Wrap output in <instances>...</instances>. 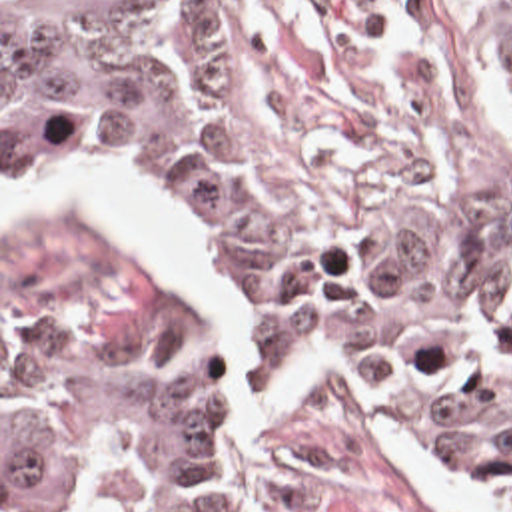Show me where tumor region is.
Here are the masks:
<instances>
[{
	"instance_id": "obj_1",
	"label": "tumor region",
	"mask_w": 512,
	"mask_h": 512,
	"mask_svg": "<svg viewBox=\"0 0 512 512\" xmlns=\"http://www.w3.org/2000/svg\"><path fill=\"white\" fill-rule=\"evenodd\" d=\"M2 154L146 168L192 238L226 344L363 362L512 491V214L397 248H294L244 180L190 0H2ZM2 505L252 512L178 290L126 278L2 316Z\"/></svg>"
}]
</instances>
